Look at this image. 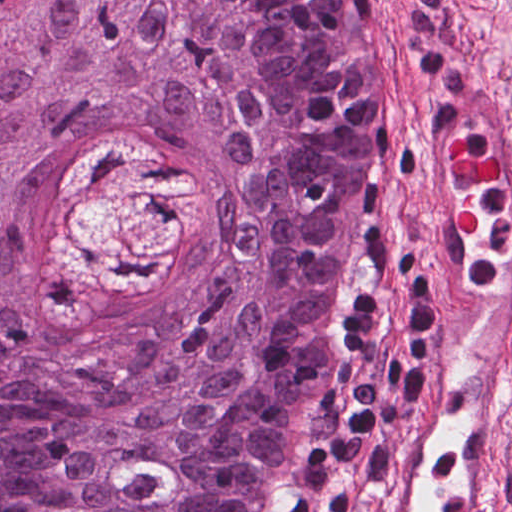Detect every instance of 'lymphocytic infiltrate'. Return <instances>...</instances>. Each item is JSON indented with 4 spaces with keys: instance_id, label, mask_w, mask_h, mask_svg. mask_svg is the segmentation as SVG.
<instances>
[{
    "instance_id": "lymphocytic-infiltrate-1",
    "label": "lymphocytic infiltrate",
    "mask_w": 512,
    "mask_h": 512,
    "mask_svg": "<svg viewBox=\"0 0 512 512\" xmlns=\"http://www.w3.org/2000/svg\"><path fill=\"white\" fill-rule=\"evenodd\" d=\"M407 261L380 264L362 288L337 343L325 400L280 494L276 512H352L388 378L408 354Z\"/></svg>"
}]
</instances>
